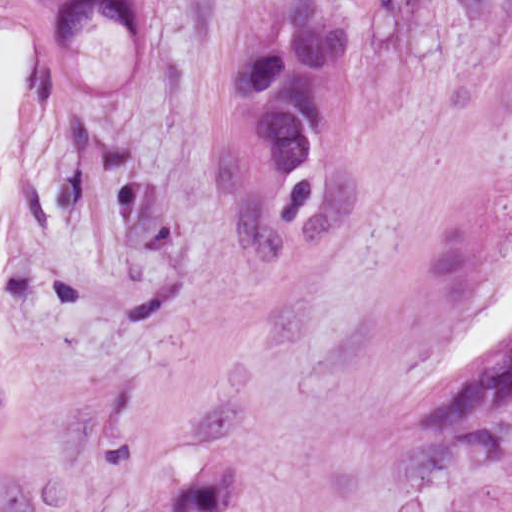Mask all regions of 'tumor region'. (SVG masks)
<instances>
[{
  "label": "tumor region",
  "instance_id": "e687c5a6",
  "mask_svg": "<svg viewBox=\"0 0 512 512\" xmlns=\"http://www.w3.org/2000/svg\"><path fill=\"white\" fill-rule=\"evenodd\" d=\"M316 0H291L281 31L256 47L233 79V99L247 120L249 153L281 170L268 222L282 232L315 221L327 165L323 95L350 69V33L318 24ZM116 22L131 36H151L147 0H70L52 29L57 49H82L89 27ZM11 395L0 380V422ZM406 429L457 451L466 461L501 457L512 435V333L466 358L399 411ZM457 512H501L485 494Z\"/></svg>",
  "mask_w": 512,
  "mask_h": 512
}]
</instances>
